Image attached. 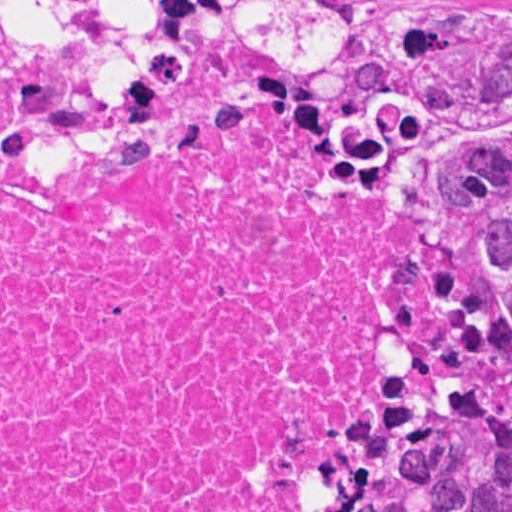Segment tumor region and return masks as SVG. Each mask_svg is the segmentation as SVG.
I'll list each match as a JSON object with an SVG mask.
<instances>
[{"mask_svg":"<svg viewBox=\"0 0 512 512\" xmlns=\"http://www.w3.org/2000/svg\"><path fill=\"white\" fill-rule=\"evenodd\" d=\"M0 6L53 109L102 139L215 80L440 149L469 197V301L373 512H512V0H394L366 42L367 0Z\"/></svg>","mask_w":512,"mask_h":512,"instance_id":"e687c5a6","label":"tumor region"}]
</instances>
